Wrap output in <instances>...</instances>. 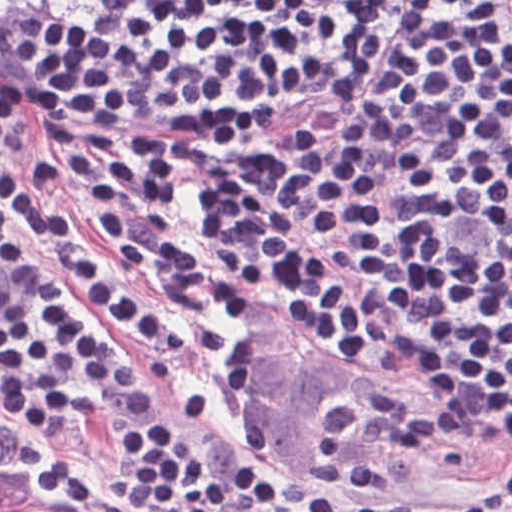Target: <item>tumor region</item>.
<instances>
[{"label":"tumor region","mask_w":512,"mask_h":512,"mask_svg":"<svg viewBox=\"0 0 512 512\" xmlns=\"http://www.w3.org/2000/svg\"><path fill=\"white\" fill-rule=\"evenodd\" d=\"M0 512H87L51 489L29 466L0 447Z\"/></svg>","instance_id":"tumor-region-1"}]
</instances>
